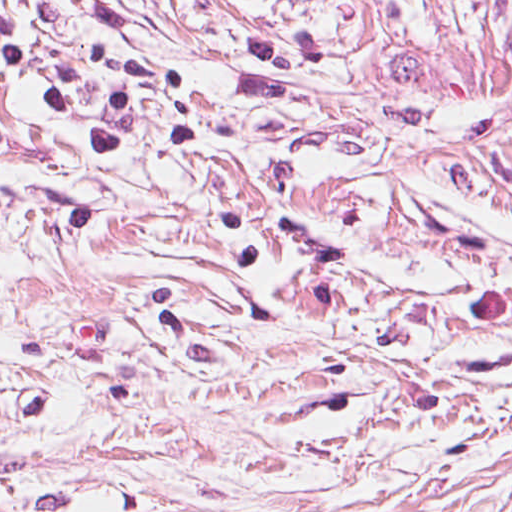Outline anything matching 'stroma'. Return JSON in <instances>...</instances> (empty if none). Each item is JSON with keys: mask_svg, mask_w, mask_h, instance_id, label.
Masks as SVG:
<instances>
[{"mask_svg": "<svg viewBox=\"0 0 512 512\" xmlns=\"http://www.w3.org/2000/svg\"><path fill=\"white\" fill-rule=\"evenodd\" d=\"M0 512H512V464L0 355Z\"/></svg>", "mask_w": 512, "mask_h": 512, "instance_id": "35a3bbf8", "label": "stroma"}]
</instances>
